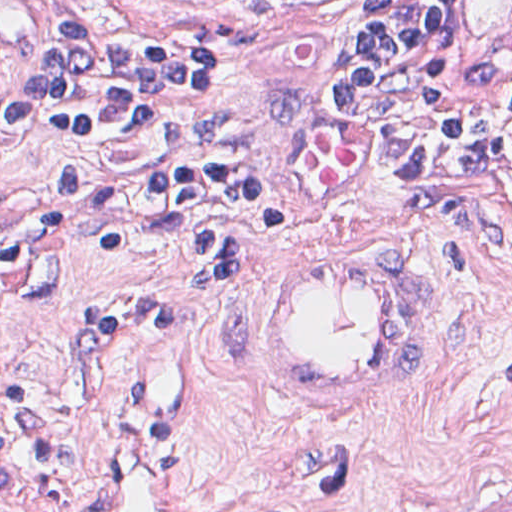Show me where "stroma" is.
Instances as JSON below:
<instances>
[{
	"label": "stroma",
	"mask_w": 512,
	"mask_h": 512,
	"mask_svg": "<svg viewBox=\"0 0 512 512\" xmlns=\"http://www.w3.org/2000/svg\"><path fill=\"white\" fill-rule=\"evenodd\" d=\"M104 32L209 49L217 90L192 117L120 142L242 163L289 215V243H366L413 260L424 360L390 404L349 417L284 407L249 360L240 291L204 283L139 197L1 261V196L92 167L97 147L23 130L1 163L0 512H92L104 451L150 414L191 512H484L512 504V158L495 184L452 173L435 120H352L331 92L367 0H63ZM512 29V0H460Z\"/></svg>",
	"instance_id": "stroma-1"
}]
</instances>
